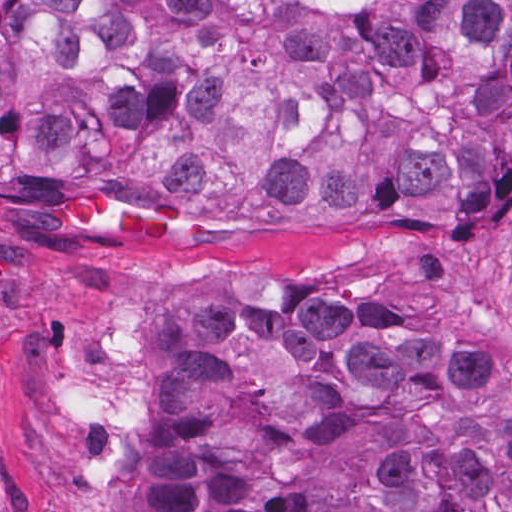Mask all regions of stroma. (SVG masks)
<instances>
[{
	"instance_id": "1",
	"label": "stroma",
	"mask_w": 512,
	"mask_h": 512,
	"mask_svg": "<svg viewBox=\"0 0 512 512\" xmlns=\"http://www.w3.org/2000/svg\"><path fill=\"white\" fill-rule=\"evenodd\" d=\"M384 299L411 336L477 339L511 363L512 172L455 219L176 213L96 185L0 193V512H132L146 432L182 412L147 388L143 346L195 304L253 293Z\"/></svg>"
}]
</instances>
